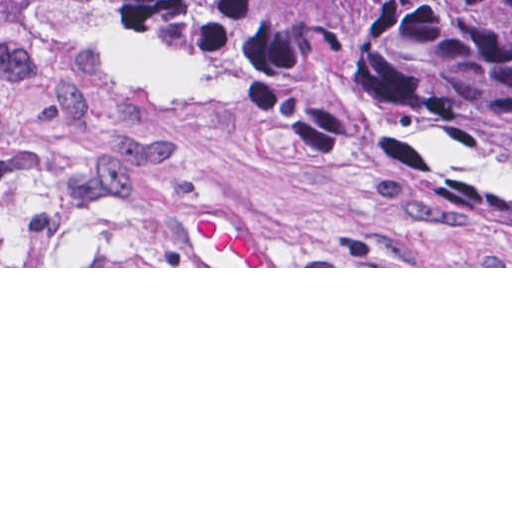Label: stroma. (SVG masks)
<instances>
[{
  "instance_id": "stroma-1",
  "label": "stroma",
  "mask_w": 512,
  "mask_h": 512,
  "mask_svg": "<svg viewBox=\"0 0 512 512\" xmlns=\"http://www.w3.org/2000/svg\"><path fill=\"white\" fill-rule=\"evenodd\" d=\"M0 268H512V207L0 29Z\"/></svg>"
}]
</instances>
